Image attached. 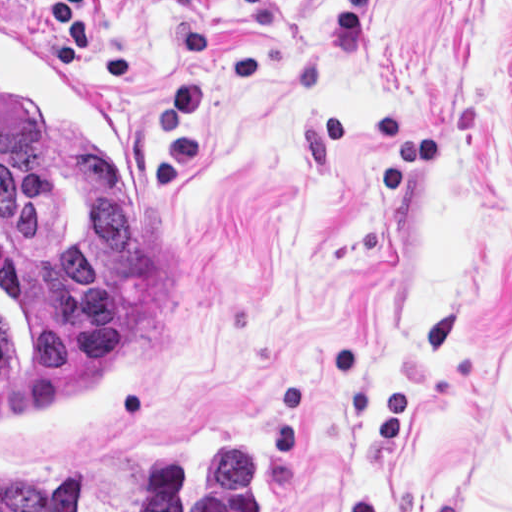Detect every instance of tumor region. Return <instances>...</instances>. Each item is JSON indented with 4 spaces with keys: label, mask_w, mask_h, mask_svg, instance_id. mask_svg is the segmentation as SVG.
<instances>
[{
    "label": "tumor region",
    "mask_w": 512,
    "mask_h": 512,
    "mask_svg": "<svg viewBox=\"0 0 512 512\" xmlns=\"http://www.w3.org/2000/svg\"><path fill=\"white\" fill-rule=\"evenodd\" d=\"M1 512H94L92 474H1ZM135 512H255L242 448H173L138 466Z\"/></svg>",
    "instance_id": "1"
}]
</instances>
